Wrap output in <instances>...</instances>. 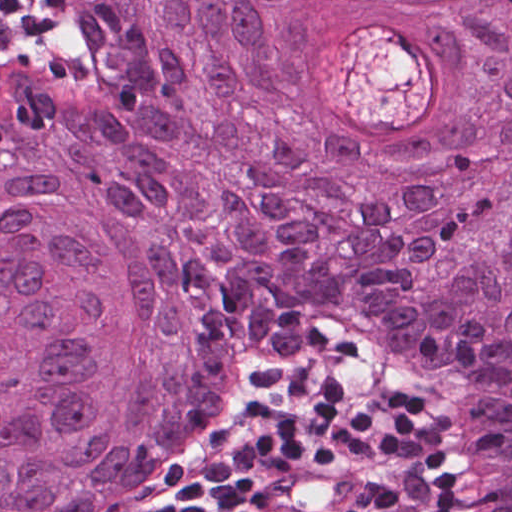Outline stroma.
Instances as JSON below:
<instances>
[{"label": "stroma", "instance_id": "stroma-1", "mask_svg": "<svg viewBox=\"0 0 512 512\" xmlns=\"http://www.w3.org/2000/svg\"><path fill=\"white\" fill-rule=\"evenodd\" d=\"M68 56L55 29V52L36 60L18 54L0 59V71L56 68ZM369 380L395 390L441 428L449 457L447 499L434 512H463L470 498V423L465 389L438 364L408 358L349 328L333 334L328 351L313 358H267L252 365L238 413L213 462L166 505L151 512H205L225 468L259 407L302 383Z\"/></svg>", "mask_w": 512, "mask_h": 512}]
</instances>
